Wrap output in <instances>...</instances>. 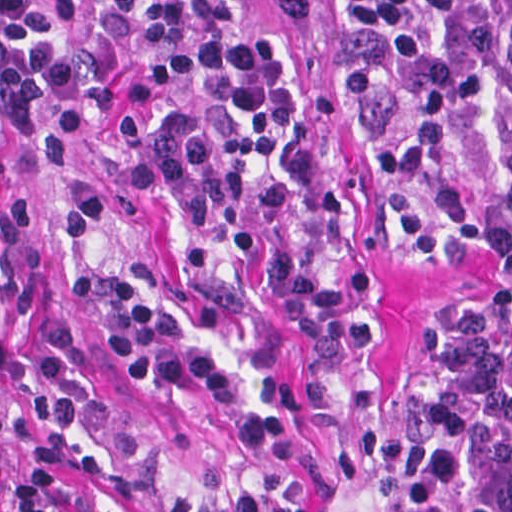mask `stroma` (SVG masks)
Segmentation results:
<instances>
[{
  "label": "stroma",
  "mask_w": 512,
  "mask_h": 512,
  "mask_svg": "<svg viewBox=\"0 0 512 512\" xmlns=\"http://www.w3.org/2000/svg\"><path fill=\"white\" fill-rule=\"evenodd\" d=\"M60 1L83 27V108L98 136L134 137L166 117L199 113L226 148L277 172L296 254L364 304L371 350L359 387L282 302L265 266L204 222L175 190L148 212L104 229L102 265H161L193 329L309 426L332 457L338 482L328 488L283 467L250 464L231 445L210 400L188 386H144L126 374L78 285L57 272L39 244L38 187L6 138L29 234V307L40 351L53 512H165L177 500L224 504L257 492L281 498L296 512H406L397 392L464 306L491 300L512 316V258L489 244L445 260L419 255L403 211L397 143L378 110L339 72L335 0L250 3L315 95L364 228V255L352 270H329L314 255L306 208L287 170L203 107L104 0Z\"/></svg>",
  "instance_id": "obj_1"
}]
</instances>
